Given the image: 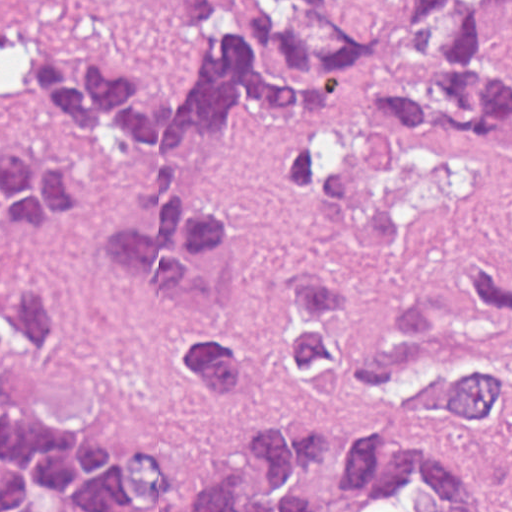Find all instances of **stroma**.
Returning <instances> with one entry per match:
<instances>
[{
  "instance_id": "stroma-1",
  "label": "stroma",
  "mask_w": 512,
  "mask_h": 512,
  "mask_svg": "<svg viewBox=\"0 0 512 512\" xmlns=\"http://www.w3.org/2000/svg\"><path fill=\"white\" fill-rule=\"evenodd\" d=\"M262 0H220L236 22ZM409 0H326L337 24L365 42L400 30ZM493 47L512 72V6L495 14ZM50 48L76 70L135 67L160 93H179L202 48L172 23L166 0H0V139L77 171L92 186L68 219L0 241V265L59 278L73 297L66 332L24 363L0 372V402L52 421L103 447H140L168 467L180 503L219 464L248 476V428L301 415L329 435L310 480L322 512H355L341 478L342 447L375 435L444 453L485 479L501 512H512V442L498 432L392 413H352L304 401L281 354V296L309 267L340 284L367 312H406L438 291V267L477 255L512 275V151L423 146L376 123L369 90L344 80L339 119L351 163L390 200L397 238L372 255L308 237V219L331 192L323 176L299 204H283L266 177L278 142L315 128V111L282 117L240 107L216 135L186 146L192 199L236 211L244 247L222 289V323L248 339L257 381L245 400L207 398L172 363L175 325L163 294L116 267L114 236L147 229L137 186L154 184L156 151L122 135L87 133L38 116L17 69V48Z\"/></svg>"
}]
</instances>
